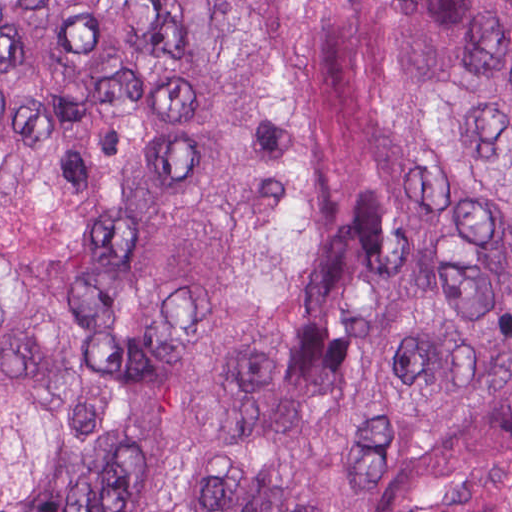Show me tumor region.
Instances as JSON below:
<instances>
[{
    "instance_id": "1",
    "label": "tumor region",
    "mask_w": 512,
    "mask_h": 512,
    "mask_svg": "<svg viewBox=\"0 0 512 512\" xmlns=\"http://www.w3.org/2000/svg\"><path fill=\"white\" fill-rule=\"evenodd\" d=\"M0 512H512V0H0Z\"/></svg>"
}]
</instances>
